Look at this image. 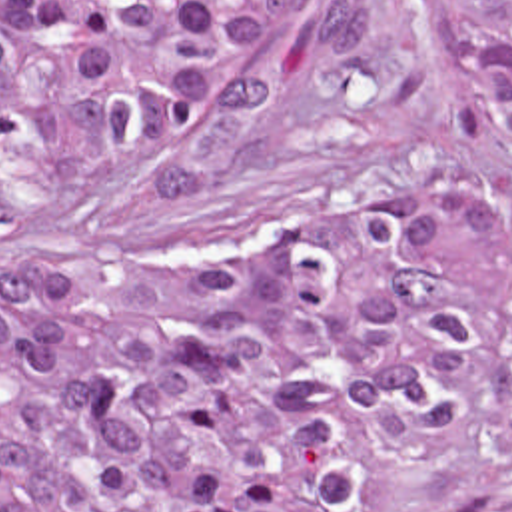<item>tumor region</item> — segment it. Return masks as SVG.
Segmentation results:
<instances>
[{
    "label": "tumor region",
    "mask_w": 512,
    "mask_h": 512,
    "mask_svg": "<svg viewBox=\"0 0 512 512\" xmlns=\"http://www.w3.org/2000/svg\"><path fill=\"white\" fill-rule=\"evenodd\" d=\"M460 68L512 150V0H452ZM271 36L321 74L369 0H0V166L53 194L197 126ZM512 352V200L335 246L255 232L191 268L0 246V512H383L355 416L454 448Z\"/></svg>",
    "instance_id": "e687c5a6"
}]
</instances>
